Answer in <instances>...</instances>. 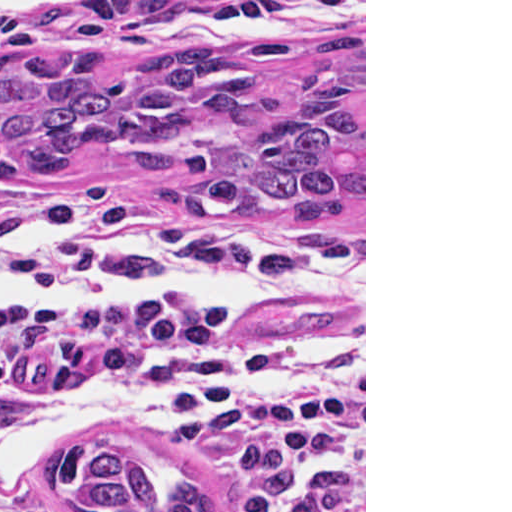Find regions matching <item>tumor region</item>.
Returning <instances> with one entry per match:
<instances>
[{"instance_id": "tumor-region-1", "label": "tumor region", "mask_w": 512, "mask_h": 512, "mask_svg": "<svg viewBox=\"0 0 512 512\" xmlns=\"http://www.w3.org/2000/svg\"><path fill=\"white\" fill-rule=\"evenodd\" d=\"M118 64L109 51L0 62V184L92 155L205 226L322 231L364 210V35L325 37L283 83L210 47L123 78ZM48 477L79 512H223L185 455L116 436L81 433Z\"/></svg>"}]
</instances>
